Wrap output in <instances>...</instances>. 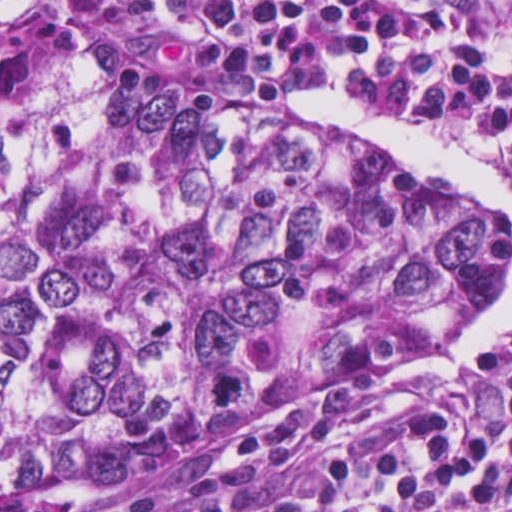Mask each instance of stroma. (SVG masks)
I'll list each match as a JSON object with an SVG mask.
<instances>
[{
    "label": "stroma",
    "mask_w": 512,
    "mask_h": 512,
    "mask_svg": "<svg viewBox=\"0 0 512 512\" xmlns=\"http://www.w3.org/2000/svg\"><path fill=\"white\" fill-rule=\"evenodd\" d=\"M53 1L65 14L74 19L78 27L114 37L96 26L67 0ZM170 63L185 72L196 74L180 62ZM297 118L320 135L366 148L409 167L424 177L442 181L439 176L394 149L358 138L315 119L302 116ZM511 265L512 239L507 225V263L493 288ZM486 359L476 372L465 380L388 383L394 373L350 392H309L289 396L273 405L267 413L251 418L230 447L224 451L177 458L96 493L65 496L52 491L16 492L10 499L0 502V512H107L143 495L174 493L184 489L189 479L218 472L224 465L240 459L243 439L250 431L264 428L283 429L306 415H331L341 423L346 438L359 425L387 412L443 401L454 400L464 411L472 415L495 414L502 408L500 398L473 382Z\"/></svg>",
    "instance_id": "1"
}]
</instances>
